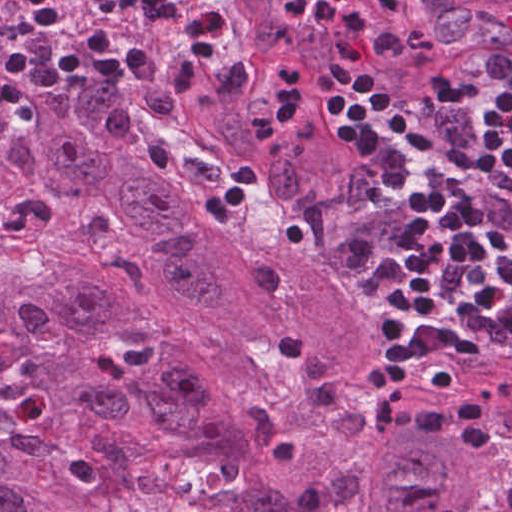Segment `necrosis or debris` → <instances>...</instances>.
Returning <instances> with one entry per match:
<instances>
[{"instance_id": "necrosis-or-debris-1", "label": "necrosis or debris", "mask_w": 512, "mask_h": 512, "mask_svg": "<svg viewBox=\"0 0 512 512\" xmlns=\"http://www.w3.org/2000/svg\"><path fill=\"white\" fill-rule=\"evenodd\" d=\"M147 474L161 487L166 512H215L212 499L225 472L205 460L170 454Z\"/></svg>"}]
</instances>
